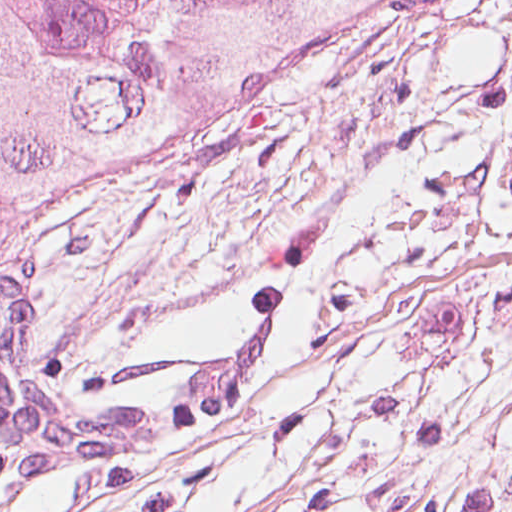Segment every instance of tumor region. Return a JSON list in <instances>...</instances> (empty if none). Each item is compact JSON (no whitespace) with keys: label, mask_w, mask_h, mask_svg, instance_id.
<instances>
[{"label":"tumor region","mask_w":512,"mask_h":512,"mask_svg":"<svg viewBox=\"0 0 512 512\" xmlns=\"http://www.w3.org/2000/svg\"><path fill=\"white\" fill-rule=\"evenodd\" d=\"M392 0H0V252L293 92Z\"/></svg>","instance_id":"tumor-region-1"}]
</instances>
